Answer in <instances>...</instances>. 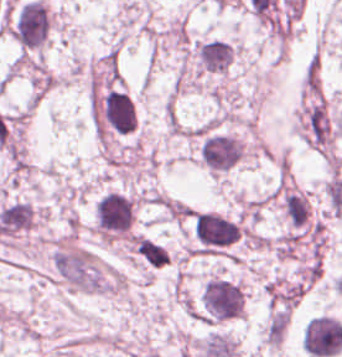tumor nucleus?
Here are the masks:
<instances>
[{
    "label": "tumor nucleus",
    "instance_id": "tumor-nucleus-1",
    "mask_svg": "<svg viewBox=\"0 0 342 357\" xmlns=\"http://www.w3.org/2000/svg\"><path fill=\"white\" fill-rule=\"evenodd\" d=\"M303 348L314 357H327L342 349V325L330 315H316L303 327Z\"/></svg>",
    "mask_w": 342,
    "mask_h": 357
}]
</instances>
